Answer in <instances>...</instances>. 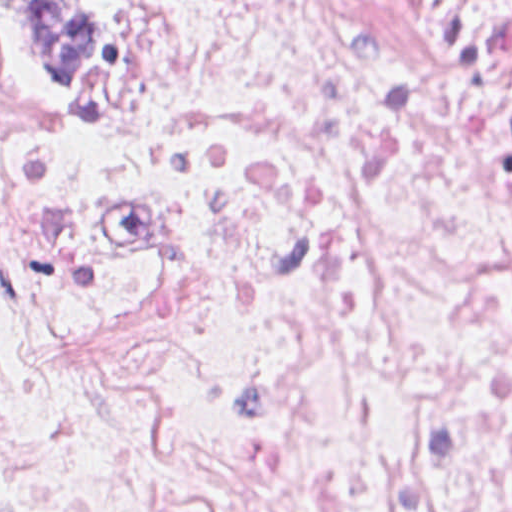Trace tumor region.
Instances as JSON below:
<instances>
[{"label": "tumor region", "instance_id": "e687c5a6", "mask_svg": "<svg viewBox=\"0 0 512 512\" xmlns=\"http://www.w3.org/2000/svg\"><path fill=\"white\" fill-rule=\"evenodd\" d=\"M13 50L49 82L90 76L117 35L110 0H0Z\"/></svg>", "mask_w": 512, "mask_h": 512}]
</instances>
